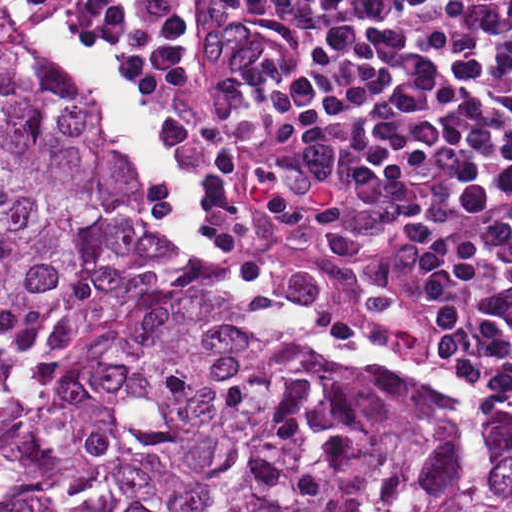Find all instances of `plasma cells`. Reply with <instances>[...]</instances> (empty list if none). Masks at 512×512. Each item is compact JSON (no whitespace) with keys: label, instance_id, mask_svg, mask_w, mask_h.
Instances as JSON below:
<instances>
[{"label":"plasma cells","instance_id":"1","mask_svg":"<svg viewBox=\"0 0 512 512\" xmlns=\"http://www.w3.org/2000/svg\"><path fill=\"white\" fill-rule=\"evenodd\" d=\"M73 18L180 139L232 261L512 397V1H76Z\"/></svg>","mask_w":512,"mask_h":512}]
</instances>
